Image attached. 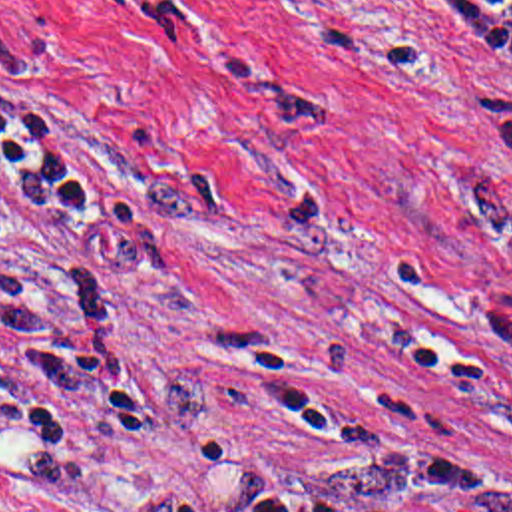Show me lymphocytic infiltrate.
<instances>
[{"label":"lymphocytic infiltrate","mask_w":512,"mask_h":512,"mask_svg":"<svg viewBox=\"0 0 512 512\" xmlns=\"http://www.w3.org/2000/svg\"><path fill=\"white\" fill-rule=\"evenodd\" d=\"M445 25L453 55L489 77L512 81V0H457ZM0 146L13 164L11 192L101 234L99 194L53 134L23 111H0Z\"/></svg>","instance_id":"obj_1"}]
</instances>
